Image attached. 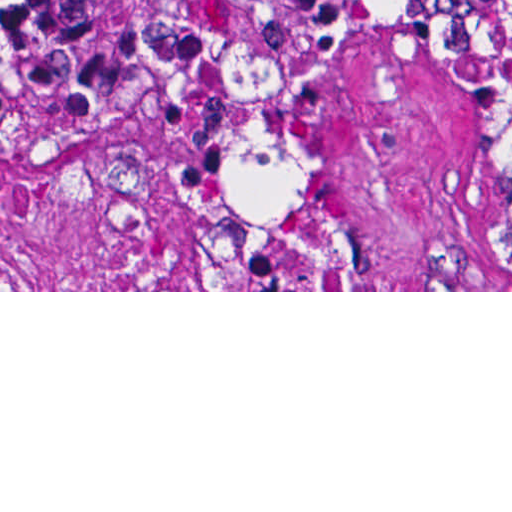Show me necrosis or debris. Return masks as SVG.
<instances>
[{"mask_svg":"<svg viewBox=\"0 0 512 512\" xmlns=\"http://www.w3.org/2000/svg\"><path fill=\"white\" fill-rule=\"evenodd\" d=\"M512 224V16L463 43ZM200 211L212 290H349L347 221L304 128L274 99L240 93L210 121Z\"/></svg>","mask_w":512,"mask_h":512,"instance_id":"1","label":"necrosis or debris"}]
</instances>
